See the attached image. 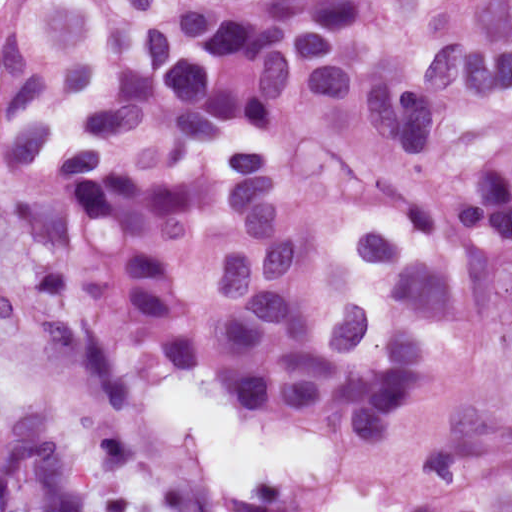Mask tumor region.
<instances>
[{
  "label": "tumor region",
  "instance_id": "tumor-region-1",
  "mask_svg": "<svg viewBox=\"0 0 512 512\" xmlns=\"http://www.w3.org/2000/svg\"><path fill=\"white\" fill-rule=\"evenodd\" d=\"M0 202L95 394L164 367L249 425L414 446L465 354H512V0H0ZM0 512H101L44 397L0 419ZM398 512H512V430Z\"/></svg>",
  "mask_w": 512,
  "mask_h": 512
}]
</instances>
